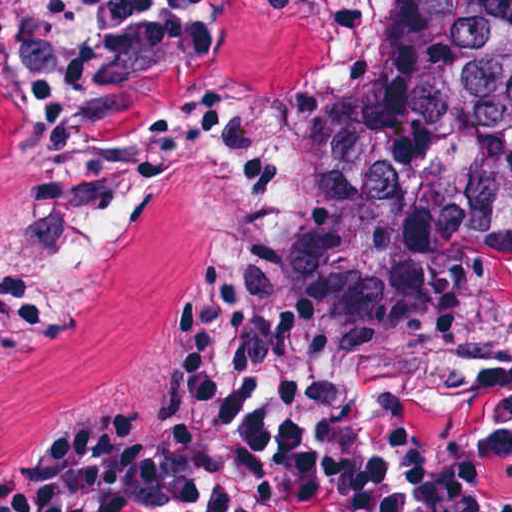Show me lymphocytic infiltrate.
Here are the masks:
<instances>
[{"mask_svg": "<svg viewBox=\"0 0 512 512\" xmlns=\"http://www.w3.org/2000/svg\"><path fill=\"white\" fill-rule=\"evenodd\" d=\"M218 4L0 0V102L35 131L52 221L89 234L165 173L269 188L278 151L259 117L108 147L121 86L212 54ZM44 294L0 287V303L36 310ZM481 446L487 464L400 454L374 402L324 373L265 280L217 275L183 306L163 357L62 447L0 453V512H512V382Z\"/></svg>", "mask_w": 512, "mask_h": 512, "instance_id": "f902f5d3", "label": "lymphocytic infiltrate"}]
</instances>
